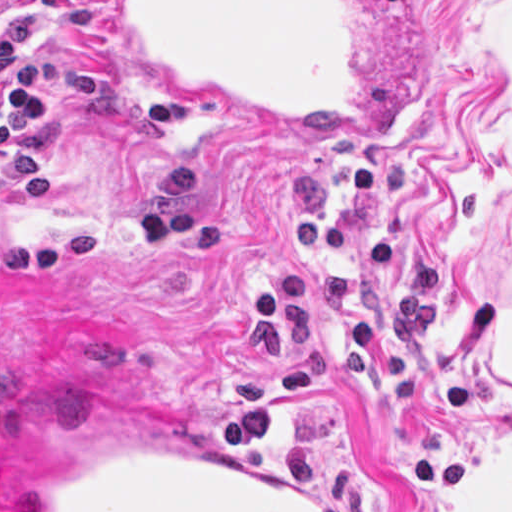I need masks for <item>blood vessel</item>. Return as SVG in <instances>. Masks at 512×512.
Listing matches in <instances>:
<instances>
[{
    "mask_svg": "<svg viewBox=\"0 0 512 512\" xmlns=\"http://www.w3.org/2000/svg\"><path fill=\"white\" fill-rule=\"evenodd\" d=\"M107 36L145 85L312 140L390 145L413 90V0H107ZM7 512H338L202 434L83 452Z\"/></svg>",
    "mask_w": 512,
    "mask_h": 512,
    "instance_id": "8fb6f2fc",
    "label": "blood vessel"
}]
</instances>
